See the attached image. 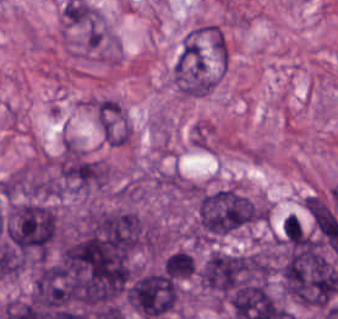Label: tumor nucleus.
Wrapping results in <instances>:
<instances>
[{"label": "tumor nucleus", "instance_id": "tumor-nucleus-3", "mask_svg": "<svg viewBox=\"0 0 338 319\" xmlns=\"http://www.w3.org/2000/svg\"><path fill=\"white\" fill-rule=\"evenodd\" d=\"M56 190L81 193L107 184L109 173L102 160L72 140H65L53 161Z\"/></svg>", "mask_w": 338, "mask_h": 319}, {"label": "tumor nucleus", "instance_id": "tumor-nucleus-4", "mask_svg": "<svg viewBox=\"0 0 338 319\" xmlns=\"http://www.w3.org/2000/svg\"><path fill=\"white\" fill-rule=\"evenodd\" d=\"M93 109L104 140L112 145L123 143L129 132L123 108L113 99L102 98Z\"/></svg>", "mask_w": 338, "mask_h": 319}, {"label": "tumor nucleus", "instance_id": "tumor-nucleus-1", "mask_svg": "<svg viewBox=\"0 0 338 319\" xmlns=\"http://www.w3.org/2000/svg\"><path fill=\"white\" fill-rule=\"evenodd\" d=\"M58 230L56 208L45 201L10 204L1 222L4 238L25 259H44L55 245Z\"/></svg>", "mask_w": 338, "mask_h": 319}, {"label": "tumor nucleus", "instance_id": "tumor-nucleus-2", "mask_svg": "<svg viewBox=\"0 0 338 319\" xmlns=\"http://www.w3.org/2000/svg\"><path fill=\"white\" fill-rule=\"evenodd\" d=\"M259 216V204L237 189H201L195 233L200 238H215L255 223Z\"/></svg>", "mask_w": 338, "mask_h": 319}]
</instances>
